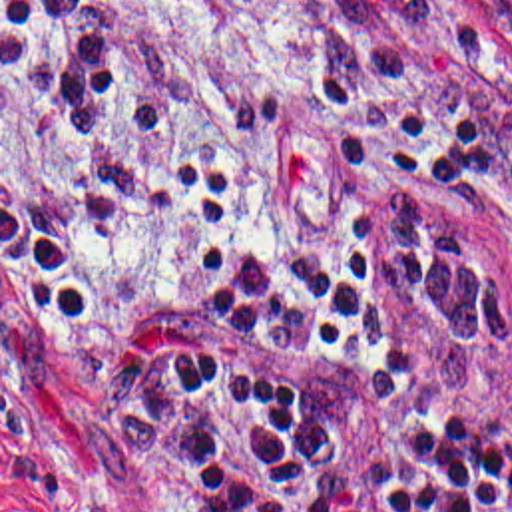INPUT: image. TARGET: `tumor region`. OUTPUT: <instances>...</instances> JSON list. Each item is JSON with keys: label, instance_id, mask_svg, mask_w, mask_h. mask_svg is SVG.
Wrapping results in <instances>:
<instances>
[{"label": "tumor region", "instance_id": "obj_1", "mask_svg": "<svg viewBox=\"0 0 512 512\" xmlns=\"http://www.w3.org/2000/svg\"><path fill=\"white\" fill-rule=\"evenodd\" d=\"M271 10H358L370 0H257ZM512 34V0H490Z\"/></svg>", "mask_w": 512, "mask_h": 512}]
</instances>
